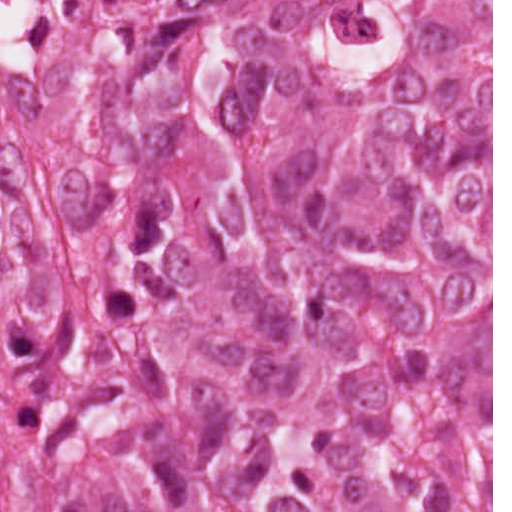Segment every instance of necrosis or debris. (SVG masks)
I'll return each instance as SVG.
<instances>
[{
    "instance_id": "obj_1",
    "label": "necrosis or debris",
    "mask_w": 512,
    "mask_h": 512,
    "mask_svg": "<svg viewBox=\"0 0 512 512\" xmlns=\"http://www.w3.org/2000/svg\"><path fill=\"white\" fill-rule=\"evenodd\" d=\"M128 0H0V193L78 254L104 189Z\"/></svg>"
}]
</instances>
